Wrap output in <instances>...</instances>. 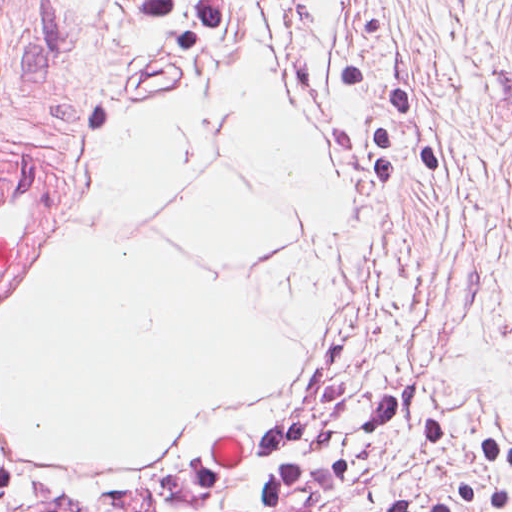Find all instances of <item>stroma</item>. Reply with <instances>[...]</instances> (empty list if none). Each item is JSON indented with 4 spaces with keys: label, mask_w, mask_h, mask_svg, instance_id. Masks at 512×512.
I'll return each instance as SVG.
<instances>
[{
    "label": "stroma",
    "mask_w": 512,
    "mask_h": 512,
    "mask_svg": "<svg viewBox=\"0 0 512 512\" xmlns=\"http://www.w3.org/2000/svg\"><path fill=\"white\" fill-rule=\"evenodd\" d=\"M258 64L332 169L338 307L295 340L289 383L147 462L21 451L0 410V481L88 490L213 462L359 360L333 422L358 468L339 512H399L464 486L458 460L426 453L422 410L373 440L365 379L512 444V0H0V175L36 152L47 162L0 294L85 221L109 141L195 82Z\"/></svg>",
    "instance_id": "35a3bbf8"
}]
</instances>
